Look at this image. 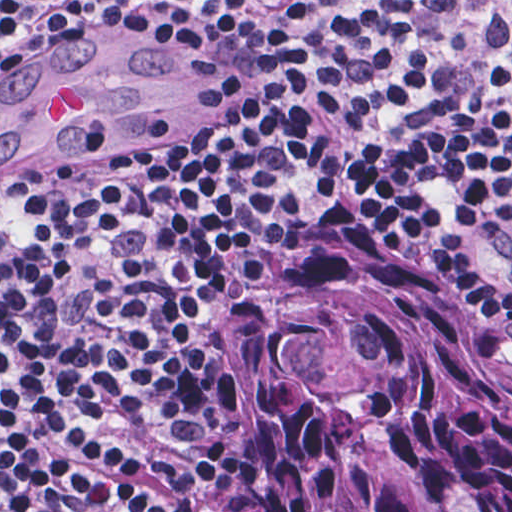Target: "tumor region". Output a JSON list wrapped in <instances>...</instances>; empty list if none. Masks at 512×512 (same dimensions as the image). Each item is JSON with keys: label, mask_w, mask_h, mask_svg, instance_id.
<instances>
[{"label": "tumor region", "mask_w": 512, "mask_h": 512, "mask_svg": "<svg viewBox=\"0 0 512 512\" xmlns=\"http://www.w3.org/2000/svg\"><path fill=\"white\" fill-rule=\"evenodd\" d=\"M484 254L501 336L332 194L240 295L230 350L267 512H512V235Z\"/></svg>", "instance_id": "1"}]
</instances>
